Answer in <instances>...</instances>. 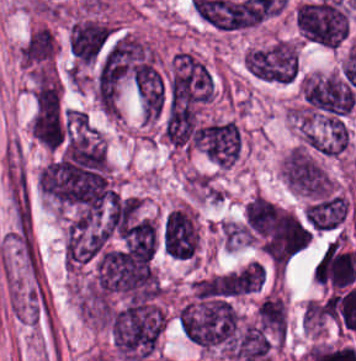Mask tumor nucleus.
Returning a JSON list of instances; mask_svg holds the SVG:
<instances>
[{"mask_svg": "<svg viewBox=\"0 0 356 361\" xmlns=\"http://www.w3.org/2000/svg\"><path fill=\"white\" fill-rule=\"evenodd\" d=\"M214 91L213 74L197 56L180 50L173 53L165 81V110L168 113L206 104Z\"/></svg>", "mask_w": 356, "mask_h": 361, "instance_id": "2", "label": "tumor nucleus"}, {"mask_svg": "<svg viewBox=\"0 0 356 361\" xmlns=\"http://www.w3.org/2000/svg\"><path fill=\"white\" fill-rule=\"evenodd\" d=\"M313 277L330 289L351 287L356 280V253L344 235L331 239L319 255Z\"/></svg>", "mask_w": 356, "mask_h": 361, "instance_id": "7", "label": "tumor nucleus"}, {"mask_svg": "<svg viewBox=\"0 0 356 361\" xmlns=\"http://www.w3.org/2000/svg\"><path fill=\"white\" fill-rule=\"evenodd\" d=\"M243 67L264 83H290L297 76V46L276 40L245 51Z\"/></svg>", "mask_w": 356, "mask_h": 361, "instance_id": "4", "label": "tumor nucleus"}, {"mask_svg": "<svg viewBox=\"0 0 356 361\" xmlns=\"http://www.w3.org/2000/svg\"><path fill=\"white\" fill-rule=\"evenodd\" d=\"M300 90L309 109L327 114L345 115L354 99L350 84L331 73H306Z\"/></svg>", "mask_w": 356, "mask_h": 361, "instance_id": "5", "label": "tumor nucleus"}, {"mask_svg": "<svg viewBox=\"0 0 356 361\" xmlns=\"http://www.w3.org/2000/svg\"><path fill=\"white\" fill-rule=\"evenodd\" d=\"M132 84L140 118L149 124L159 120L165 107V85L156 60L143 63Z\"/></svg>", "mask_w": 356, "mask_h": 361, "instance_id": "8", "label": "tumor nucleus"}, {"mask_svg": "<svg viewBox=\"0 0 356 361\" xmlns=\"http://www.w3.org/2000/svg\"><path fill=\"white\" fill-rule=\"evenodd\" d=\"M111 344L122 361H141L155 352L165 325L160 290L113 304L107 313Z\"/></svg>", "mask_w": 356, "mask_h": 361, "instance_id": "1", "label": "tumor nucleus"}, {"mask_svg": "<svg viewBox=\"0 0 356 361\" xmlns=\"http://www.w3.org/2000/svg\"><path fill=\"white\" fill-rule=\"evenodd\" d=\"M349 211L346 195L333 191L308 199L302 216L305 224L314 231L330 232L340 229Z\"/></svg>", "mask_w": 356, "mask_h": 361, "instance_id": "9", "label": "tumor nucleus"}, {"mask_svg": "<svg viewBox=\"0 0 356 361\" xmlns=\"http://www.w3.org/2000/svg\"><path fill=\"white\" fill-rule=\"evenodd\" d=\"M33 138L45 148L59 150L67 118L59 93H34L29 117Z\"/></svg>", "mask_w": 356, "mask_h": 361, "instance_id": "6", "label": "tumor nucleus"}, {"mask_svg": "<svg viewBox=\"0 0 356 361\" xmlns=\"http://www.w3.org/2000/svg\"><path fill=\"white\" fill-rule=\"evenodd\" d=\"M56 43L49 28L39 26L30 32L18 48V60L29 71L49 67L55 58Z\"/></svg>", "mask_w": 356, "mask_h": 361, "instance_id": "11", "label": "tumor nucleus"}, {"mask_svg": "<svg viewBox=\"0 0 356 361\" xmlns=\"http://www.w3.org/2000/svg\"><path fill=\"white\" fill-rule=\"evenodd\" d=\"M279 175L287 190L306 200L331 190L328 171L303 144H296L284 152Z\"/></svg>", "mask_w": 356, "mask_h": 361, "instance_id": "3", "label": "tumor nucleus"}, {"mask_svg": "<svg viewBox=\"0 0 356 361\" xmlns=\"http://www.w3.org/2000/svg\"><path fill=\"white\" fill-rule=\"evenodd\" d=\"M113 31L107 21L80 18L69 29V48L75 63L86 64L93 60Z\"/></svg>", "mask_w": 356, "mask_h": 361, "instance_id": "10", "label": "tumor nucleus"}]
</instances>
